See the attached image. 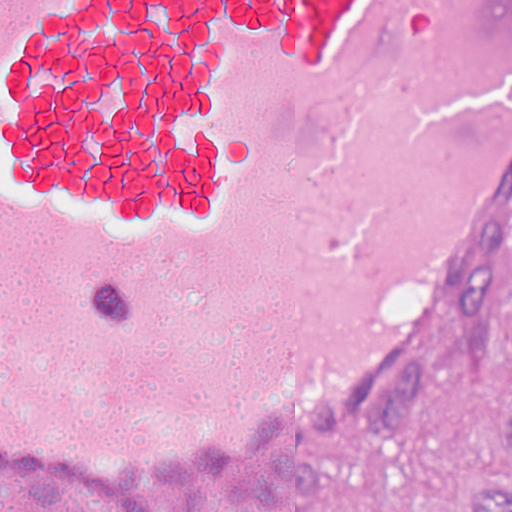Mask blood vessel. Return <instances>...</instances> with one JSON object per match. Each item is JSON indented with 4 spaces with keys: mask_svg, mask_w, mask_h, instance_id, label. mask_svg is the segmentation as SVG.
<instances>
[{
    "mask_svg": "<svg viewBox=\"0 0 512 512\" xmlns=\"http://www.w3.org/2000/svg\"><path fill=\"white\" fill-rule=\"evenodd\" d=\"M511 170L512 0H0V463L310 447Z\"/></svg>",
    "mask_w": 512,
    "mask_h": 512,
    "instance_id": "obj_1",
    "label": "blood vessel"
}]
</instances>
